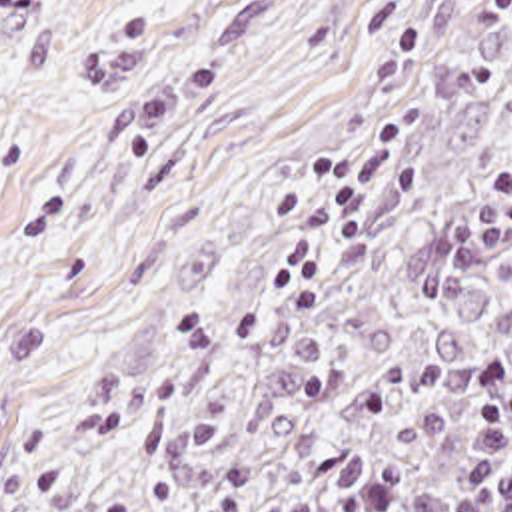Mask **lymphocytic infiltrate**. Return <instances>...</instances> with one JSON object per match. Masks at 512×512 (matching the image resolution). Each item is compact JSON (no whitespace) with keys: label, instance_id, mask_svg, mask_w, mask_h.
I'll return each mask as SVG.
<instances>
[{"label":"lymphocytic infiltrate","instance_id":"f902f5d3","mask_svg":"<svg viewBox=\"0 0 512 512\" xmlns=\"http://www.w3.org/2000/svg\"><path fill=\"white\" fill-rule=\"evenodd\" d=\"M479 392L462 483L440 487L420 475L388 473L334 512H512V364H487Z\"/></svg>","mask_w":512,"mask_h":512}]
</instances>
